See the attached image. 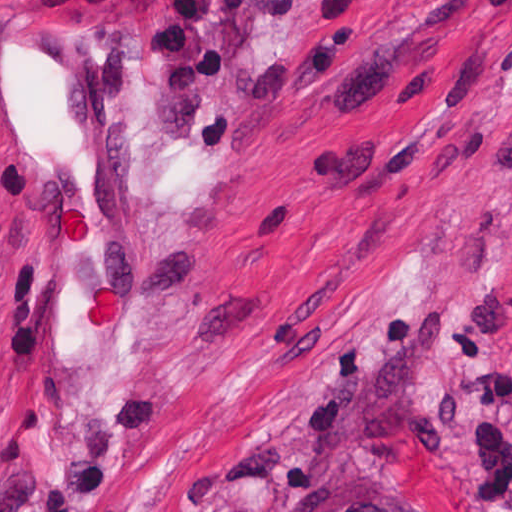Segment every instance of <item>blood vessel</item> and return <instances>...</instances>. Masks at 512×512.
Returning a JSON list of instances; mask_svg holds the SVG:
<instances>
[{"label":"blood vessel","mask_w":512,"mask_h":512,"mask_svg":"<svg viewBox=\"0 0 512 512\" xmlns=\"http://www.w3.org/2000/svg\"><path fill=\"white\" fill-rule=\"evenodd\" d=\"M10 369L48 454L106 426L153 344L146 92L93 0H0Z\"/></svg>","instance_id":"obj_1"}]
</instances>
